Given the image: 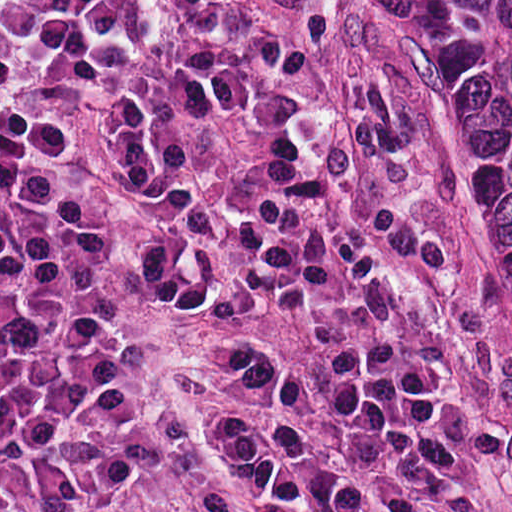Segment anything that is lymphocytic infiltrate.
I'll list each match as a JSON object with an SVG mask.
<instances>
[{"mask_svg":"<svg viewBox=\"0 0 512 512\" xmlns=\"http://www.w3.org/2000/svg\"><path fill=\"white\" fill-rule=\"evenodd\" d=\"M0 512H507L456 267L306 86V0H0Z\"/></svg>","mask_w":512,"mask_h":512,"instance_id":"f902f5d3","label":"lymphocytic infiltrate"}]
</instances>
